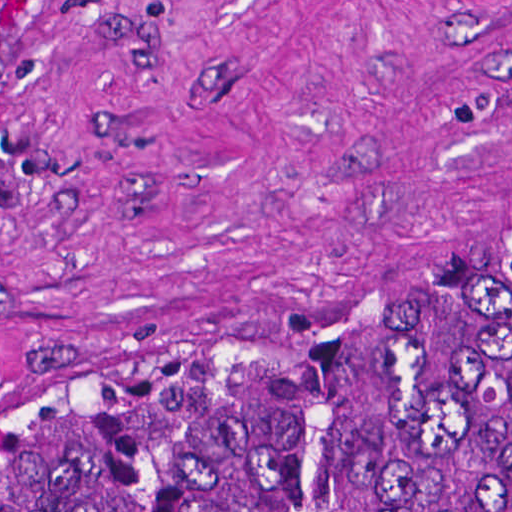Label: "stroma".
Wrapping results in <instances>:
<instances>
[{"mask_svg":"<svg viewBox=\"0 0 512 512\" xmlns=\"http://www.w3.org/2000/svg\"><path fill=\"white\" fill-rule=\"evenodd\" d=\"M0 414L196 396L512 272V0H0Z\"/></svg>","mask_w":512,"mask_h":512,"instance_id":"1","label":"stroma"}]
</instances>
